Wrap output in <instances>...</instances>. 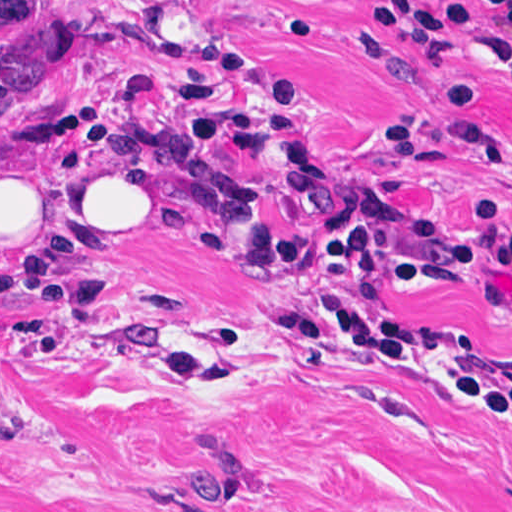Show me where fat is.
Instances as JSON below:
<instances>
[{"mask_svg":"<svg viewBox=\"0 0 512 512\" xmlns=\"http://www.w3.org/2000/svg\"><path fill=\"white\" fill-rule=\"evenodd\" d=\"M0 226L15 255H30L145 240L166 220L129 187V172L0 151Z\"/></svg>","mask_w":512,"mask_h":512,"instance_id":"obj_1","label":"fat"}]
</instances>
